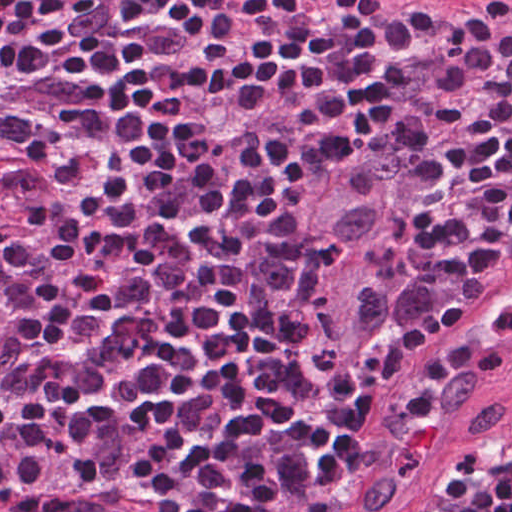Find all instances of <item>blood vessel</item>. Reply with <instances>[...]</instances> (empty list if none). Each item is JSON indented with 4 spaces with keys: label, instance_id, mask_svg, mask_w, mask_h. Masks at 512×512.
Wrapping results in <instances>:
<instances>
[{
    "label": "blood vessel",
    "instance_id": "obj_1",
    "mask_svg": "<svg viewBox=\"0 0 512 512\" xmlns=\"http://www.w3.org/2000/svg\"><path fill=\"white\" fill-rule=\"evenodd\" d=\"M512 377V258L419 339L387 377L345 484L348 512H393ZM0 492V512H170L152 481Z\"/></svg>",
    "mask_w": 512,
    "mask_h": 512
}]
</instances>
